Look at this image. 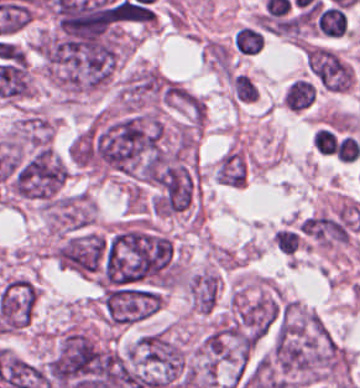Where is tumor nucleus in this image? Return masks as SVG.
<instances>
[{
	"instance_id": "1",
	"label": "tumor nucleus",
	"mask_w": 360,
	"mask_h": 388,
	"mask_svg": "<svg viewBox=\"0 0 360 388\" xmlns=\"http://www.w3.org/2000/svg\"><path fill=\"white\" fill-rule=\"evenodd\" d=\"M256 365L281 388H301L339 377L340 345L320 316L282 305Z\"/></svg>"
},
{
	"instance_id": "2",
	"label": "tumor nucleus",
	"mask_w": 360,
	"mask_h": 388,
	"mask_svg": "<svg viewBox=\"0 0 360 388\" xmlns=\"http://www.w3.org/2000/svg\"><path fill=\"white\" fill-rule=\"evenodd\" d=\"M187 288L192 308L209 314L220 297V277L215 269L203 268L189 275Z\"/></svg>"
},
{
	"instance_id": "3",
	"label": "tumor nucleus",
	"mask_w": 360,
	"mask_h": 388,
	"mask_svg": "<svg viewBox=\"0 0 360 388\" xmlns=\"http://www.w3.org/2000/svg\"><path fill=\"white\" fill-rule=\"evenodd\" d=\"M215 177L223 184L243 187L247 181V158L237 148H230L217 163Z\"/></svg>"
}]
</instances>
